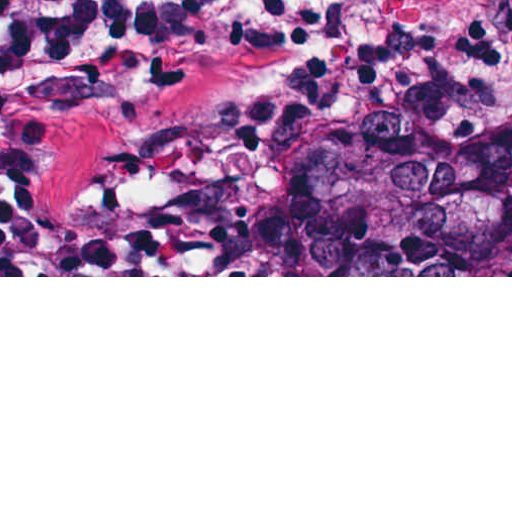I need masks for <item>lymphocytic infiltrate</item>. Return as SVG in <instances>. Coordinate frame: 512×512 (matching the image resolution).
Here are the masks:
<instances>
[{"label":"lymphocytic infiltrate","mask_w":512,"mask_h":512,"mask_svg":"<svg viewBox=\"0 0 512 512\" xmlns=\"http://www.w3.org/2000/svg\"><path fill=\"white\" fill-rule=\"evenodd\" d=\"M357 0H0V275H172L149 231L40 203V157L89 96L153 84L238 47L325 38Z\"/></svg>","instance_id":"obj_1"}]
</instances>
